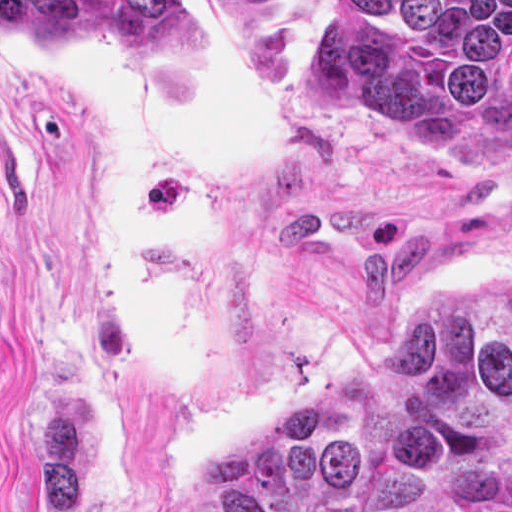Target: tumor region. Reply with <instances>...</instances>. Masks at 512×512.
<instances>
[{"label":"tumor region","mask_w":512,"mask_h":512,"mask_svg":"<svg viewBox=\"0 0 512 512\" xmlns=\"http://www.w3.org/2000/svg\"><path fill=\"white\" fill-rule=\"evenodd\" d=\"M292 86L396 141L503 136L512 1H325ZM178 512H512V274L422 297L387 355L220 462Z\"/></svg>","instance_id":"tumor-region-1"}]
</instances>
